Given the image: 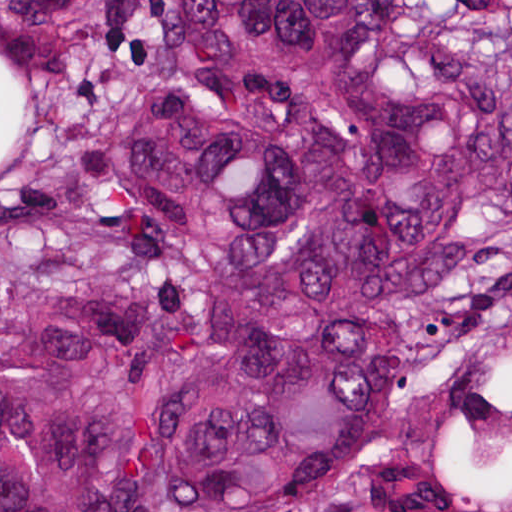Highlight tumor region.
<instances>
[{"instance_id": "e687c5a6", "label": "tumor region", "mask_w": 512, "mask_h": 512, "mask_svg": "<svg viewBox=\"0 0 512 512\" xmlns=\"http://www.w3.org/2000/svg\"><path fill=\"white\" fill-rule=\"evenodd\" d=\"M0 512H512V0H0Z\"/></svg>"}]
</instances>
